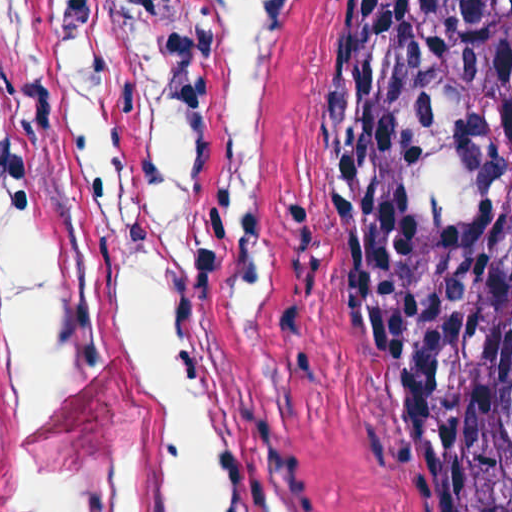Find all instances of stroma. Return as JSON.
<instances>
[{
  "mask_svg": "<svg viewBox=\"0 0 512 512\" xmlns=\"http://www.w3.org/2000/svg\"><path fill=\"white\" fill-rule=\"evenodd\" d=\"M181 0H0V512H46L128 452L118 360L32 355L9 292L95 177ZM335 0H244L238 162L204 243V413L244 512H457L403 379L306 296L298 210Z\"/></svg>",
  "mask_w": 512,
  "mask_h": 512,
  "instance_id": "1",
  "label": "stroma"
}]
</instances>
